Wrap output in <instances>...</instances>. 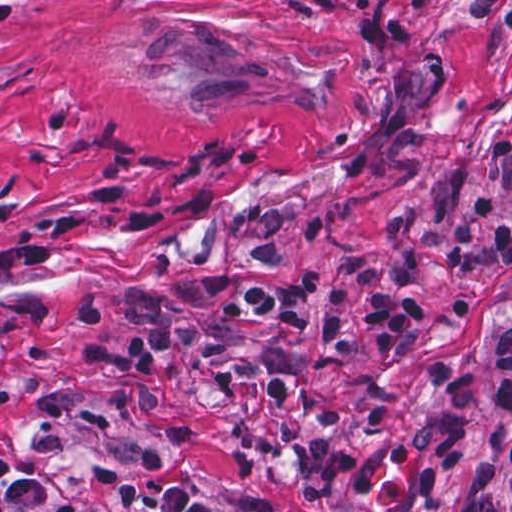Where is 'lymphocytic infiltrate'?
I'll list each match as a JSON object with an SVG mask.
<instances>
[{"label":"lymphocytic infiltrate","mask_w":512,"mask_h":512,"mask_svg":"<svg viewBox=\"0 0 512 512\" xmlns=\"http://www.w3.org/2000/svg\"><path fill=\"white\" fill-rule=\"evenodd\" d=\"M471 209L491 225L492 253L500 267L512 264V220L500 203L488 195H476ZM397 245L394 294L388 295L379 269L367 256L348 260V268L370 295L371 307L356 315L360 300L354 289L340 284L323 298V317L315 319L314 303L320 275L310 268L285 287L264 283L255 273H219L201 280V292L226 297L233 318H272L305 332L318 346L290 365L264 357H238L218 370L217 385L234 392L247 385L265 388L274 413L267 422H247L233 431V439L249 471L255 473L278 452L284 451L299 468V493L307 505L327 504L341 494L366 495L373 491L371 474H347L352 456L343 446H316L310 426L297 420L294 409L308 408L327 425L341 419V411L315 391L313 378L329 372L345 380L371 409L373 433L383 434L394 411L396 395L384 383L349 363L358 339L368 342L373 354L386 366L413 378H428L442 391L439 409L400 433L387 447L392 467L413 472L417 492L434 497L453 470L472 473L464 491L449 512H508L510 467L496 461H474L473 419L482 390L479 376L463 365L434 353L401 362L397 351L405 339L418 333L427 312L414 298L421 281L428 250L427 221L421 212L406 213L394 221ZM128 317L147 331H134L124 347L111 339V316L101 299L81 305L83 323L96 331L90 343L79 349L87 364L110 370L117 383L111 402L123 415L131 408L145 412L165 435L178 440L193 436L190 427L165 419L160 391L162 365L175 352L197 360H218L233 347V338L185 315L150 295L138 294L125 302ZM496 399L501 410L512 414V321L505 322L495 338ZM7 470L0 459V500L10 505H30L40 512H95L34 479L13 478L2 484ZM115 512H216L202 502L195 486L175 485L157 491L142 490L125 482L114 496Z\"/></svg>","instance_id":"lymphocytic-infiltrate-1"}]
</instances>
